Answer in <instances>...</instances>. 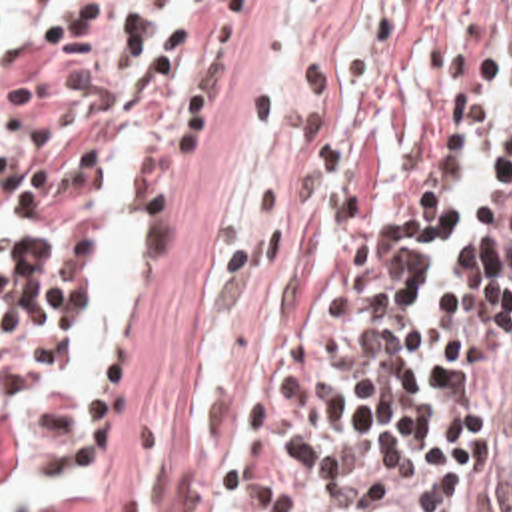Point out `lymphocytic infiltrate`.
Instances as JSON below:
<instances>
[{"instance_id":"lymphocytic-infiltrate-1","label":"lymphocytic infiltrate","mask_w":512,"mask_h":512,"mask_svg":"<svg viewBox=\"0 0 512 512\" xmlns=\"http://www.w3.org/2000/svg\"><path fill=\"white\" fill-rule=\"evenodd\" d=\"M8 6L0 481L16 393L76 337V254L170 168L207 56V2ZM499 80L489 206L429 301ZM94 417L42 403L36 461H84ZM395 467L439 475V512H512V2H351L281 152L263 291L213 417V512H347Z\"/></svg>"}]
</instances>
